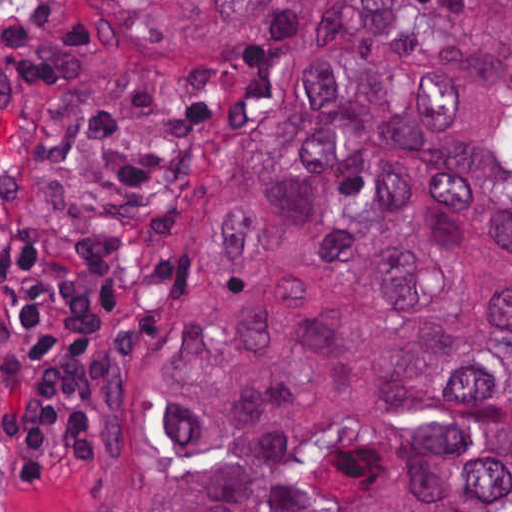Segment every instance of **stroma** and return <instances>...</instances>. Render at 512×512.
I'll return each mask as SVG.
<instances>
[{
	"instance_id": "1",
	"label": "stroma",
	"mask_w": 512,
	"mask_h": 512,
	"mask_svg": "<svg viewBox=\"0 0 512 512\" xmlns=\"http://www.w3.org/2000/svg\"><path fill=\"white\" fill-rule=\"evenodd\" d=\"M84 1L108 52L102 77L39 89L0 72V512H116L113 490L141 409L147 349L164 336L178 279L201 227L182 208L86 195L63 176V157L130 98L144 59L192 35H272L298 30L287 1L512 0H0ZM134 234L152 246V277L128 310L124 355L108 376L105 423L91 480L22 482L3 460L10 381L9 249L25 237Z\"/></svg>"
}]
</instances>
